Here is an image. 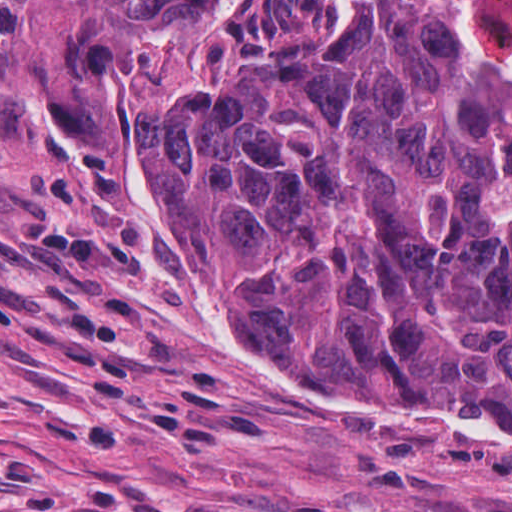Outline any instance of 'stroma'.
Here are the masks:
<instances>
[{"instance_id": "1", "label": "stroma", "mask_w": 512, "mask_h": 512, "mask_svg": "<svg viewBox=\"0 0 512 512\" xmlns=\"http://www.w3.org/2000/svg\"><path fill=\"white\" fill-rule=\"evenodd\" d=\"M0 36V512H512V427L394 418L264 361L142 187L130 97L78 154L52 84L69 0Z\"/></svg>"}]
</instances>
